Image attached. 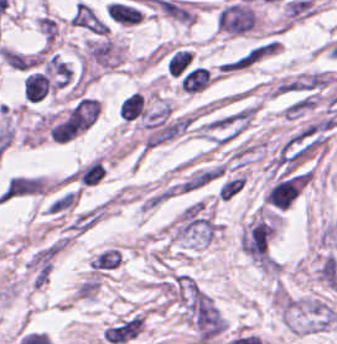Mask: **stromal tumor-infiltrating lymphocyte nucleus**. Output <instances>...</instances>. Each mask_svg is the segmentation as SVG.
<instances>
[{
  "label": "stromal tumor-infiltrating lymphocyte nucleus",
  "mask_w": 337,
  "mask_h": 344,
  "mask_svg": "<svg viewBox=\"0 0 337 344\" xmlns=\"http://www.w3.org/2000/svg\"><path fill=\"white\" fill-rule=\"evenodd\" d=\"M53 89L48 75L33 71L23 82V96L27 101H40Z\"/></svg>",
  "instance_id": "bc302bb0"
}]
</instances>
